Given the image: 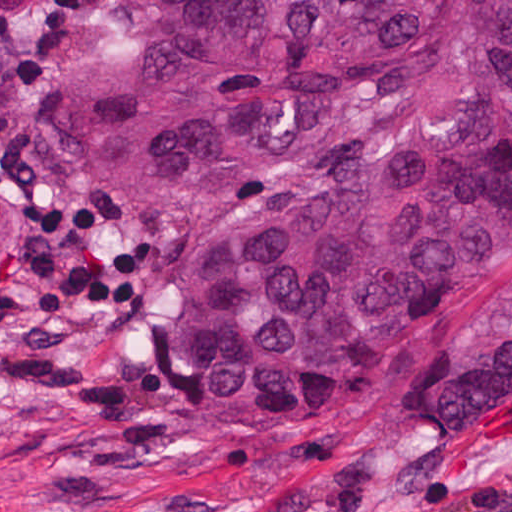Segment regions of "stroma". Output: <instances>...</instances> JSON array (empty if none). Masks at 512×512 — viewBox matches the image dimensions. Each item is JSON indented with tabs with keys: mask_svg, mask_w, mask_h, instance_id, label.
<instances>
[{
	"mask_svg": "<svg viewBox=\"0 0 512 512\" xmlns=\"http://www.w3.org/2000/svg\"><path fill=\"white\" fill-rule=\"evenodd\" d=\"M118 62L114 0H0V512H512V268L308 409L214 412L158 328L255 207L355 167L452 76H352L290 149L150 189L77 131Z\"/></svg>",
	"mask_w": 512,
	"mask_h": 512,
	"instance_id": "35a3bbf8",
	"label": "stroma"
}]
</instances>
